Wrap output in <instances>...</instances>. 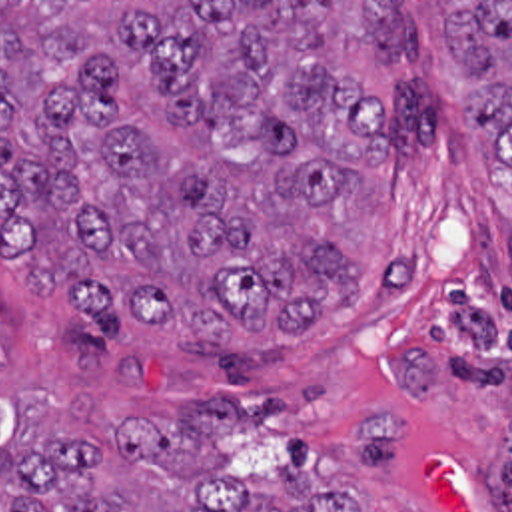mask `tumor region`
Here are the masks:
<instances>
[{
  "mask_svg": "<svg viewBox=\"0 0 512 512\" xmlns=\"http://www.w3.org/2000/svg\"><path fill=\"white\" fill-rule=\"evenodd\" d=\"M420 6L0 2L1 256L105 335L321 329L370 279L329 208L394 148L335 48L414 60ZM440 20L512 168V2ZM0 483V512H363L287 461L227 457L209 415L0 437Z\"/></svg>",
  "mask_w": 512,
  "mask_h": 512,
  "instance_id": "1",
  "label": "tumor region"
}]
</instances>
